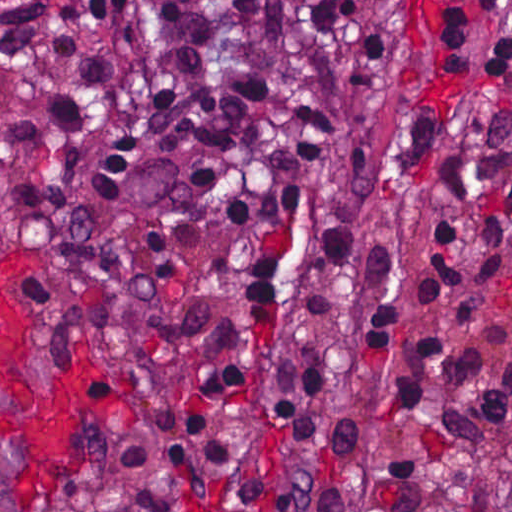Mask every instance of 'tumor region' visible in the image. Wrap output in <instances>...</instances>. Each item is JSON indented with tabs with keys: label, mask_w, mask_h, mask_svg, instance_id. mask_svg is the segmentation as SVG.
<instances>
[{
	"label": "tumor region",
	"mask_w": 512,
	"mask_h": 512,
	"mask_svg": "<svg viewBox=\"0 0 512 512\" xmlns=\"http://www.w3.org/2000/svg\"><path fill=\"white\" fill-rule=\"evenodd\" d=\"M15 399L0 392V410L16 406ZM22 463V453L10 438L0 434V512H12L11 490Z\"/></svg>",
	"instance_id": "obj_1"
}]
</instances>
